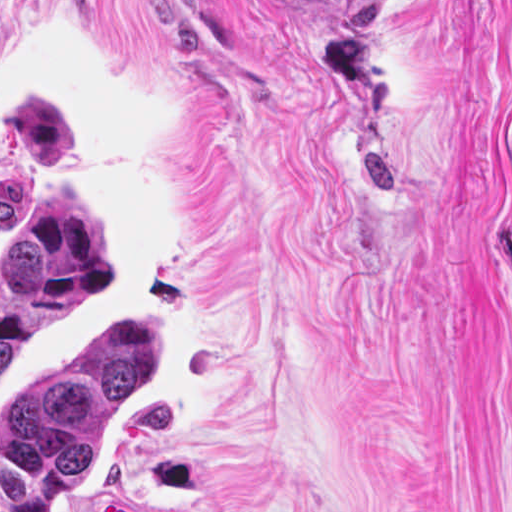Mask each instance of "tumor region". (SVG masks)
<instances>
[{
  "mask_svg": "<svg viewBox=\"0 0 512 512\" xmlns=\"http://www.w3.org/2000/svg\"><path fill=\"white\" fill-rule=\"evenodd\" d=\"M397 0H283L321 25H361ZM502 228L512 241V98L502 124ZM109 283V260L71 194L41 198L0 259V385L70 306ZM31 379L0 417V512H51L54 497L82 478L94 451L92 416L150 385L154 337L111 311L83 334L60 367Z\"/></svg>",
  "mask_w": 512,
  "mask_h": 512,
  "instance_id": "1",
  "label": "tumor region"
}]
</instances>
